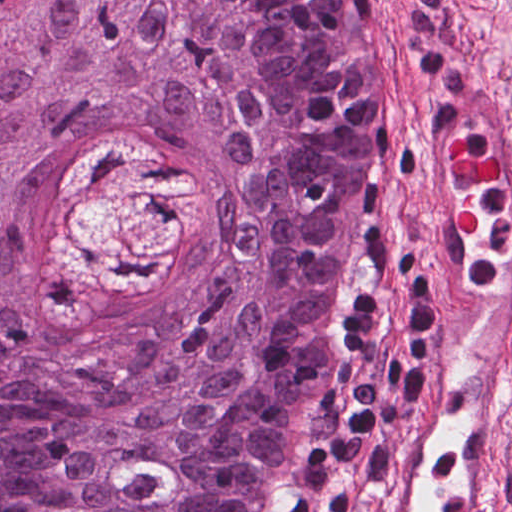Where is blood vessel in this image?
I'll list each match as a JSON object with an SVG mask.
<instances>
[{
    "instance_id": "blood-vessel-1",
    "label": "blood vessel",
    "mask_w": 512,
    "mask_h": 512,
    "mask_svg": "<svg viewBox=\"0 0 512 512\" xmlns=\"http://www.w3.org/2000/svg\"><path fill=\"white\" fill-rule=\"evenodd\" d=\"M407 354L352 512H505L512 433V97L476 69L432 105L413 175Z\"/></svg>"
}]
</instances>
